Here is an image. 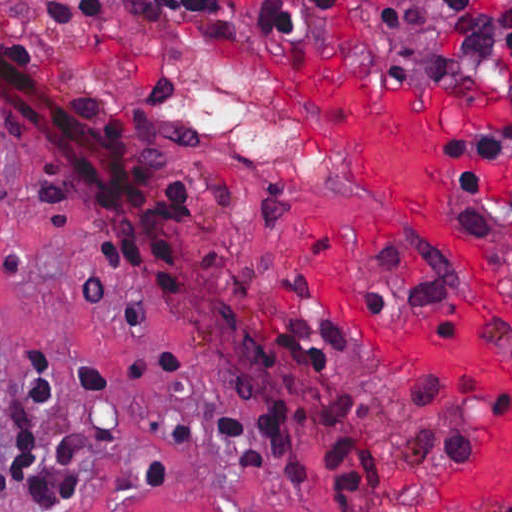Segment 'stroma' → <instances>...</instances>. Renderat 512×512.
<instances>
[{
    "mask_svg": "<svg viewBox=\"0 0 512 512\" xmlns=\"http://www.w3.org/2000/svg\"><path fill=\"white\" fill-rule=\"evenodd\" d=\"M0 1L26 18L42 17L50 2ZM0 45L96 117L131 127L153 159V187L182 181L203 209V238L179 294L161 293L99 264L87 245L84 199L42 205L29 186L27 153L0 130L12 192L0 204V471L27 444L19 412L31 349H44L63 370L51 411L20 413L34 443L51 446L63 427L88 423L114 433L85 459L71 500L35 505L15 489L0 494V512H488L444 487L504 409L498 378L381 356L315 232L377 284L393 314L433 326L456 324L472 261L346 170L310 111L307 83L432 100L439 107L433 179L447 225L512 274V159L486 185L476 228L446 156L455 126L496 105L492 89L435 74L421 79L363 42L270 38L184 17L0 16ZM140 201L96 213L130 222ZM287 318H326L349 348L330 371H312L275 351L273 331ZM84 360L113 368L112 393L83 401L75 364ZM281 404L313 480H291L274 464L240 471L226 418ZM376 436L380 493H352L324 445Z\"/></svg>",
    "mask_w": 512,
    "mask_h": 512,
    "instance_id": "35a3bbf8",
    "label": "stroma"
}]
</instances>
